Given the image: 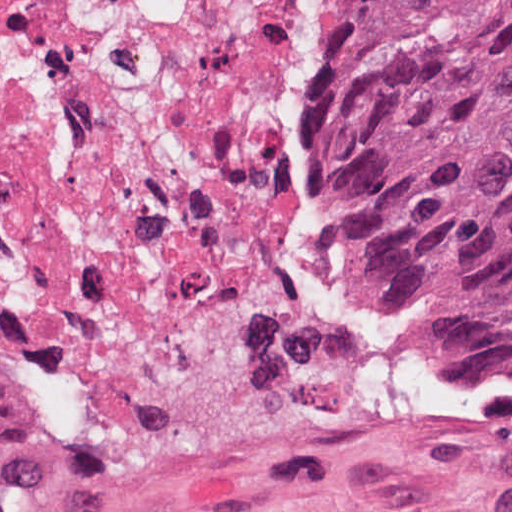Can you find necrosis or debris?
I'll return each mask as SVG.
<instances>
[{
	"label": "necrosis or debris",
	"instance_id": "necrosis-or-debris-1",
	"mask_svg": "<svg viewBox=\"0 0 512 512\" xmlns=\"http://www.w3.org/2000/svg\"><path fill=\"white\" fill-rule=\"evenodd\" d=\"M339 0H0V356L106 428L291 273L287 94Z\"/></svg>",
	"mask_w": 512,
	"mask_h": 512
}]
</instances>
